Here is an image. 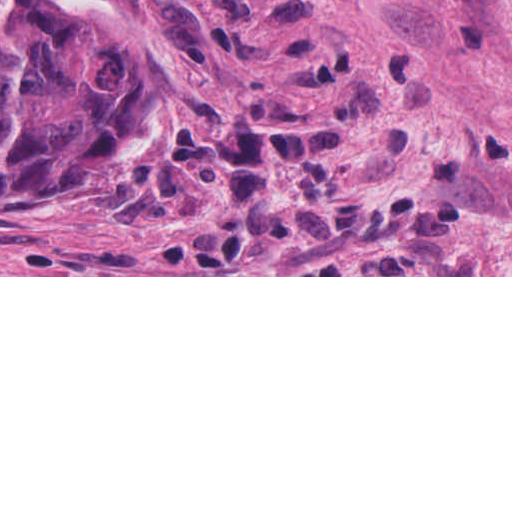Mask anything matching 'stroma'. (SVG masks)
<instances>
[{"instance_id":"stroma-1","label":"stroma","mask_w":512,"mask_h":512,"mask_svg":"<svg viewBox=\"0 0 512 512\" xmlns=\"http://www.w3.org/2000/svg\"><path fill=\"white\" fill-rule=\"evenodd\" d=\"M186 159L0 202V277H512V0H99Z\"/></svg>"}]
</instances>
